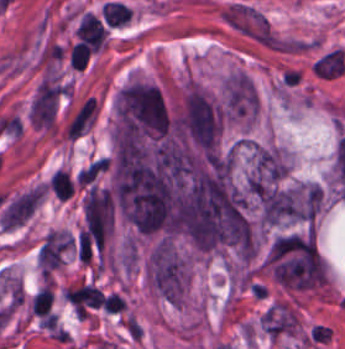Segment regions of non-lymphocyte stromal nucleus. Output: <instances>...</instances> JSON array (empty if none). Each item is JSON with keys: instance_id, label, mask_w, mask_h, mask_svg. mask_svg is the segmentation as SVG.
Wrapping results in <instances>:
<instances>
[{"instance_id": "2", "label": "non-lymphocyte stromal nucleus", "mask_w": 345, "mask_h": 349, "mask_svg": "<svg viewBox=\"0 0 345 349\" xmlns=\"http://www.w3.org/2000/svg\"><path fill=\"white\" fill-rule=\"evenodd\" d=\"M316 39L297 36H277L269 41V47L279 52H302L314 47Z\"/></svg>"}, {"instance_id": "1", "label": "non-lymphocyte stromal nucleus", "mask_w": 345, "mask_h": 349, "mask_svg": "<svg viewBox=\"0 0 345 349\" xmlns=\"http://www.w3.org/2000/svg\"><path fill=\"white\" fill-rule=\"evenodd\" d=\"M221 16L230 28L255 42L269 46L279 35L264 11L243 1L222 7Z\"/></svg>"}]
</instances>
